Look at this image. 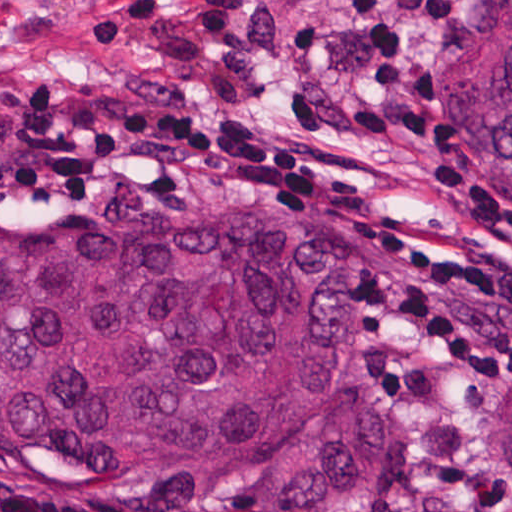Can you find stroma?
Listing matches in <instances>:
<instances>
[{"label":"stroma","instance_id":"obj_1","mask_svg":"<svg viewBox=\"0 0 512 512\" xmlns=\"http://www.w3.org/2000/svg\"><path fill=\"white\" fill-rule=\"evenodd\" d=\"M477 0H453L437 27L408 22L406 61L427 81L433 146L370 138L359 98L369 53L341 22L335 0H0V104L47 88L64 102L109 88L197 92L251 128L298 135L343 152L354 182L317 191H148L98 197L0 199L121 215H206L234 204H310L333 222L336 264L355 323V389L348 405L391 424L397 493L380 512H512V480L497 469L512 381H478L392 356L361 315L370 267L359 225H381L420 249L478 261L487 227L465 219L430 168L464 166L512 203V180L482 162L440 101L438 76L463 55V23ZM0 493L131 512H269L258 494L229 489L198 510H166L127 491L0 465Z\"/></svg>","mask_w":512,"mask_h":512}]
</instances>
